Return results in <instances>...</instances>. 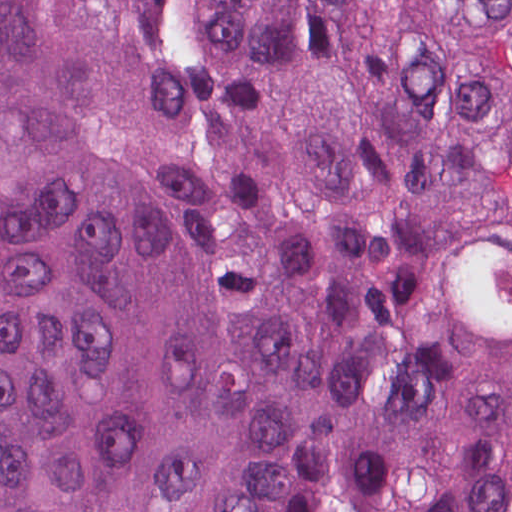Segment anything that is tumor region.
Segmentation results:
<instances>
[{
  "instance_id": "1",
  "label": "tumor region",
  "mask_w": 512,
  "mask_h": 512,
  "mask_svg": "<svg viewBox=\"0 0 512 512\" xmlns=\"http://www.w3.org/2000/svg\"><path fill=\"white\" fill-rule=\"evenodd\" d=\"M512 512V0H0V512Z\"/></svg>"
}]
</instances>
